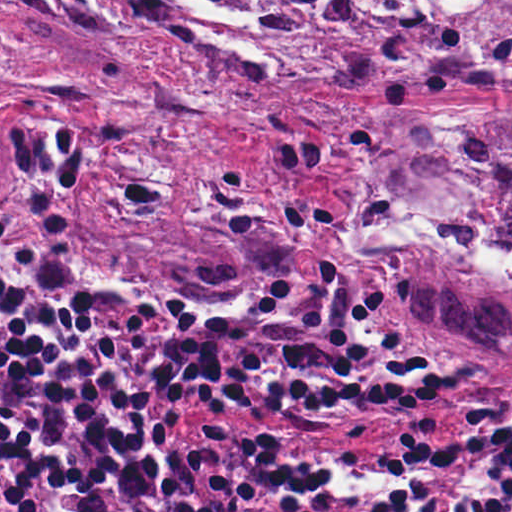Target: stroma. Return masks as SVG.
I'll use <instances>...</instances> for the list:
<instances>
[{"label":"stroma","mask_w":512,"mask_h":512,"mask_svg":"<svg viewBox=\"0 0 512 512\" xmlns=\"http://www.w3.org/2000/svg\"><path fill=\"white\" fill-rule=\"evenodd\" d=\"M206 2L262 25L264 57L217 44L172 12L159 18L160 0L136 10L0 0V106L29 122L66 198L82 265L67 288L48 291L34 227L0 204V232L31 250L35 282L75 317L96 293L207 317L267 281L331 264L373 292L425 351L512 379L506 355L426 325L343 248L360 157L345 111L398 108L356 64L320 67L301 25ZM413 109L512 115V90ZM179 265L241 282L155 285ZM212 413L262 429L412 435L441 460L420 512H436L452 488L454 454L434 426L269 423L223 403Z\"/></svg>","instance_id":"obj_1"}]
</instances>
